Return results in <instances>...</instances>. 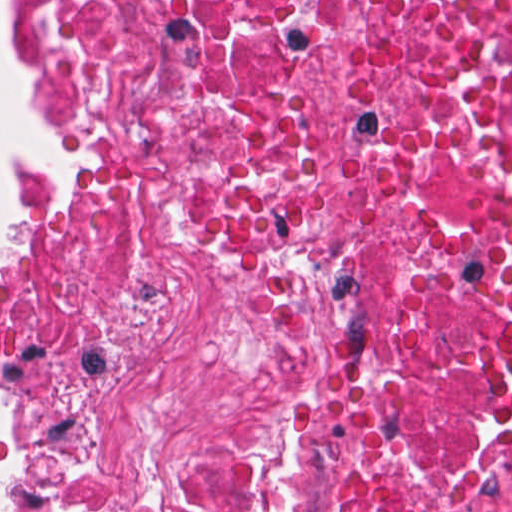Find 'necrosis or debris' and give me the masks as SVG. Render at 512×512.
Segmentation results:
<instances>
[{
    "label": "necrosis or debris",
    "mask_w": 512,
    "mask_h": 512,
    "mask_svg": "<svg viewBox=\"0 0 512 512\" xmlns=\"http://www.w3.org/2000/svg\"><path fill=\"white\" fill-rule=\"evenodd\" d=\"M26 2L0 472L512 512V0Z\"/></svg>",
    "instance_id": "4bbe7bcc"
}]
</instances>
